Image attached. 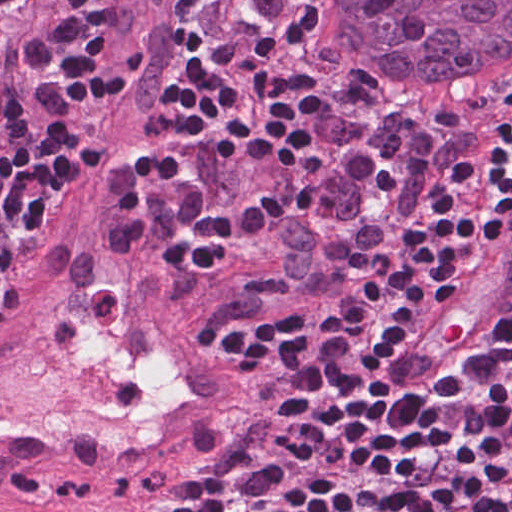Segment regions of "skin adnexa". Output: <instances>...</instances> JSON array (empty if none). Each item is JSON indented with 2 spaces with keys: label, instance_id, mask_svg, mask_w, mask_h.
Wrapping results in <instances>:
<instances>
[{
  "label": "skin adnexa",
  "instance_id": "bc48264e",
  "mask_svg": "<svg viewBox=\"0 0 512 512\" xmlns=\"http://www.w3.org/2000/svg\"><path fill=\"white\" fill-rule=\"evenodd\" d=\"M315 48L384 86L512 75V0H298Z\"/></svg>",
  "mask_w": 512,
  "mask_h": 512
}]
</instances>
